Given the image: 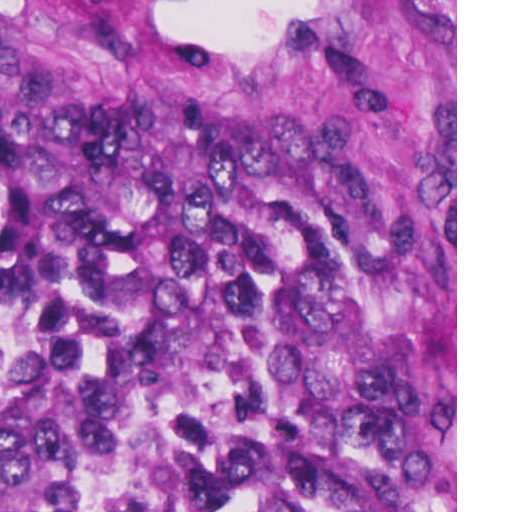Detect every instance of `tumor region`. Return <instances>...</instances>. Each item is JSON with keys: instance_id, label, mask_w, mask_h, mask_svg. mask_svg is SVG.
Here are the masks:
<instances>
[{"instance_id": "tumor-region-1", "label": "tumor region", "mask_w": 512, "mask_h": 512, "mask_svg": "<svg viewBox=\"0 0 512 512\" xmlns=\"http://www.w3.org/2000/svg\"><path fill=\"white\" fill-rule=\"evenodd\" d=\"M254 160L0 53V512H455V250Z\"/></svg>"}]
</instances>
